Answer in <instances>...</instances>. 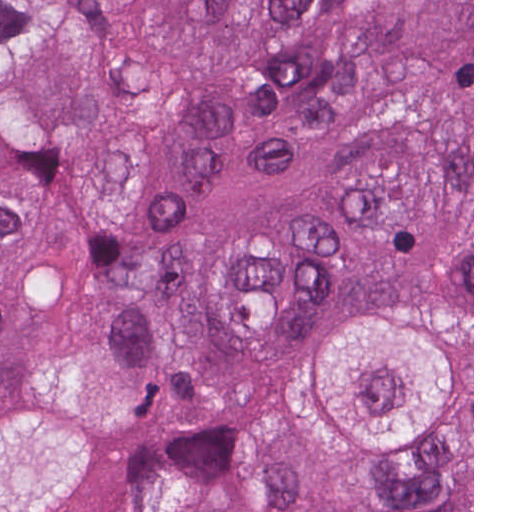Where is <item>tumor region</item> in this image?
Here are the masks:
<instances>
[{
  "label": "tumor region",
  "mask_w": 512,
  "mask_h": 512,
  "mask_svg": "<svg viewBox=\"0 0 512 512\" xmlns=\"http://www.w3.org/2000/svg\"><path fill=\"white\" fill-rule=\"evenodd\" d=\"M108 429L265 384L372 480L472 422V0H0V402ZM78 512H472L374 503L265 412L129 463Z\"/></svg>",
  "instance_id": "1"
}]
</instances>
